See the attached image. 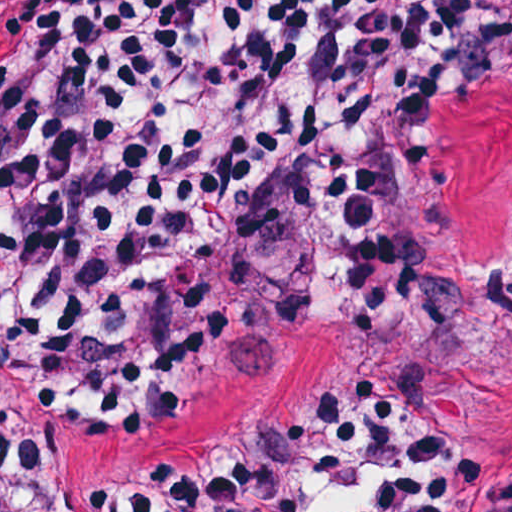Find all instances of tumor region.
Listing matches in <instances>:
<instances>
[{
  "mask_svg": "<svg viewBox=\"0 0 512 512\" xmlns=\"http://www.w3.org/2000/svg\"><path fill=\"white\" fill-rule=\"evenodd\" d=\"M449 236L476 274L512 286L510 100L467 96L452 108ZM305 350L301 322L271 325L154 397L78 412L36 494L0 512H132L239 462L279 415ZM410 379L480 444L512 452V303L426 275ZM332 512L385 510L346 488Z\"/></svg>",
  "mask_w": 512,
  "mask_h": 512,
  "instance_id": "1",
  "label": "tumor region"
}]
</instances>
